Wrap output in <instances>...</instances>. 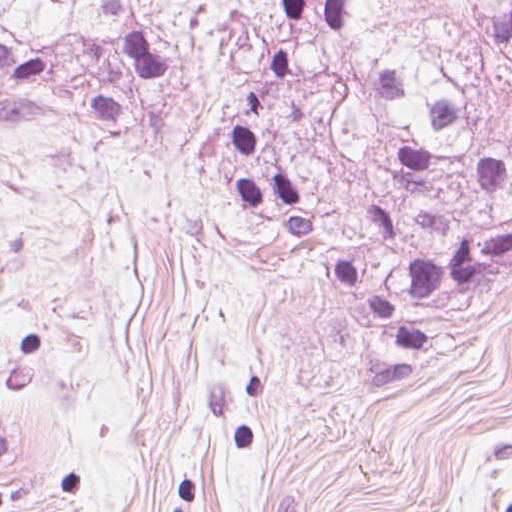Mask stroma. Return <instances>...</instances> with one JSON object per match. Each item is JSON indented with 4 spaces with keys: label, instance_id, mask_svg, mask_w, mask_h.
Here are the masks:
<instances>
[{
    "label": "stroma",
    "instance_id": "1",
    "mask_svg": "<svg viewBox=\"0 0 512 512\" xmlns=\"http://www.w3.org/2000/svg\"><path fill=\"white\" fill-rule=\"evenodd\" d=\"M0 512H512V290L386 359L160 139L0 134Z\"/></svg>",
    "mask_w": 512,
    "mask_h": 512
}]
</instances>
